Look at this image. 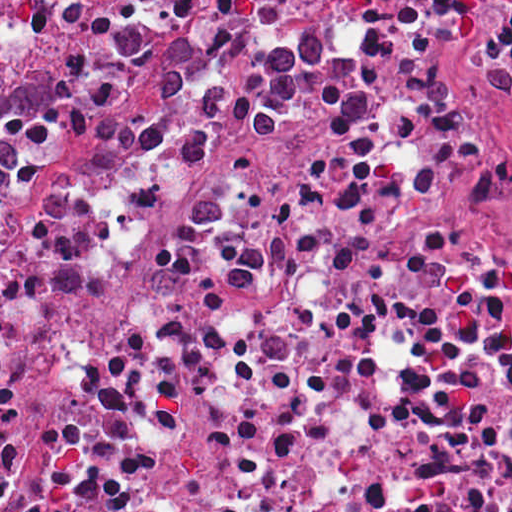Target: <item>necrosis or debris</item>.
<instances>
[{"mask_svg":"<svg viewBox=\"0 0 512 512\" xmlns=\"http://www.w3.org/2000/svg\"><path fill=\"white\" fill-rule=\"evenodd\" d=\"M113 89L0 200V512H512V0H0Z\"/></svg>","mask_w":512,"mask_h":512,"instance_id":"1","label":"necrosis or debris"}]
</instances>
